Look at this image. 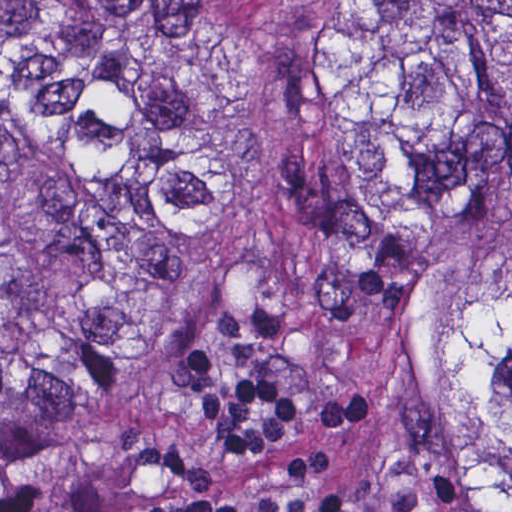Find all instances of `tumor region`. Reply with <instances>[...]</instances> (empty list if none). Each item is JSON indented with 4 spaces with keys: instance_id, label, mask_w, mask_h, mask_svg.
Returning <instances> with one entry per match:
<instances>
[{
    "instance_id": "1",
    "label": "tumor region",
    "mask_w": 512,
    "mask_h": 512,
    "mask_svg": "<svg viewBox=\"0 0 512 512\" xmlns=\"http://www.w3.org/2000/svg\"><path fill=\"white\" fill-rule=\"evenodd\" d=\"M217 287L375 393L364 512H512V1H0V476Z\"/></svg>"
}]
</instances>
